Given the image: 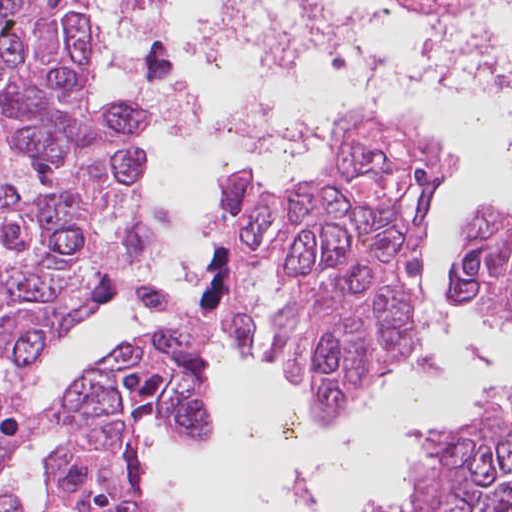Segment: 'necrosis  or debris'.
Segmentation results:
<instances>
[{
	"mask_svg": "<svg viewBox=\"0 0 512 512\" xmlns=\"http://www.w3.org/2000/svg\"><path fill=\"white\" fill-rule=\"evenodd\" d=\"M413 2L426 3L433 6L446 7L453 11L476 14L489 9L512 5V0H410Z\"/></svg>",
	"mask_w": 512,
	"mask_h": 512,
	"instance_id": "necrosis-or-debris-1",
	"label": "necrosis or debris"
}]
</instances>
